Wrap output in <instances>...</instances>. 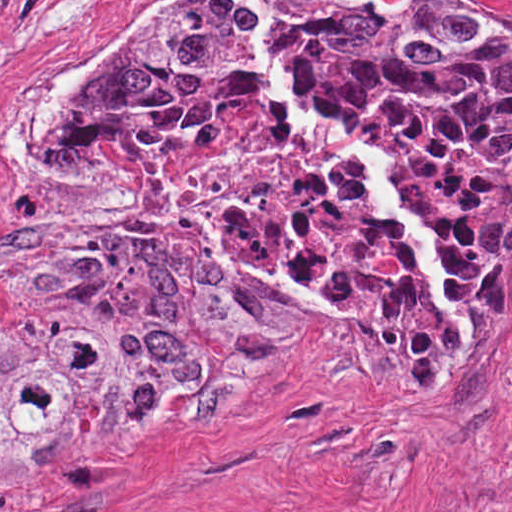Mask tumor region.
<instances>
[{"mask_svg":"<svg viewBox=\"0 0 512 512\" xmlns=\"http://www.w3.org/2000/svg\"><path fill=\"white\" fill-rule=\"evenodd\" d=\"M256 1L304 112L351 135L372 111L397 109L447 131L505 184V204L471 228L457 260L396 181L443 240L465 320L395 224L399 260L376 311L430 350L512 281V19L461 0ZM254 97L287 122L243 0H177L74 109L52 166L82 134L170 140ZM0 296L25 300L19 333L0 341V473L189 433L276 378L331 311L145 236L41 224L0 255Z\"/></svg>","mask_w":512,"mask_h":512,"instance_id":"tumor-region-1","label":"tumor region"}]
</instances>
